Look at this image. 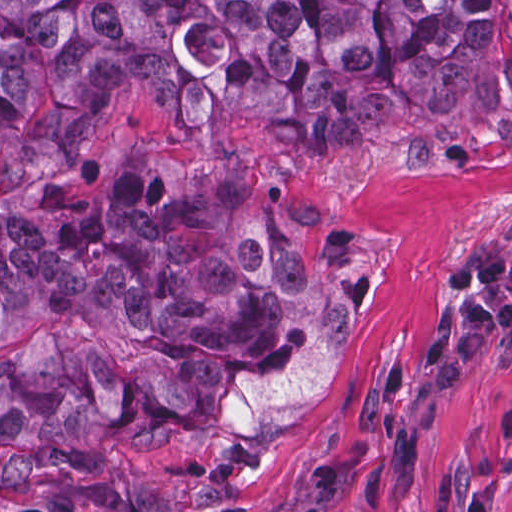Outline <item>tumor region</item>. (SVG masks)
Returning <instances> with one entry per match:
<instances>
[{
    "instance_id": "e687c5a6",
    "label": "tumor region",
    "mask_w": 512,
    "mask_h": 512,
    "mask_svg": "<svg viewBox=\"0 0 512 512\" xmlns=\"http://www.w3.org/2000/svg\"><path fill=\"white\" fill-rule=\"evenodd\" d=\"M282 153L512 155V0H0V456L212 495L300 429L369 264Z\"/></svg>"
}]
</instances>
